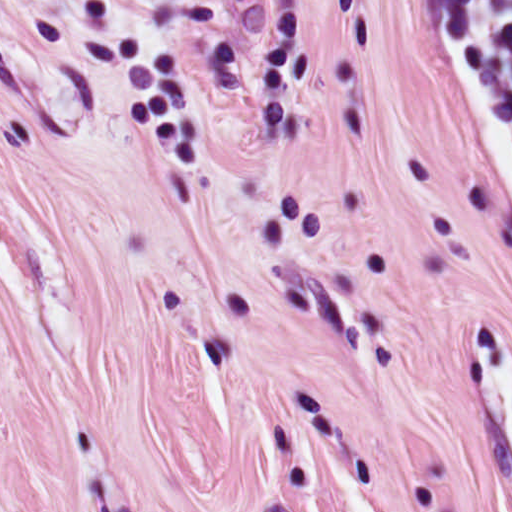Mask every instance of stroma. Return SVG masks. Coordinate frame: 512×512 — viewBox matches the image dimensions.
Instances as JSON below:
<instances>
[{"label":"stroma","instance_id":"stroma-1","mask_svg":"<svg viewBox=\"0 0 512 512\" xmlns=\"http://www.w3.org/2000/svg\"><path fill=\"white\" fill-rule=\"evenodd\" d=\"M479 352L444 0H0V512H512Z\"/></svg>","mask_w":512,"mask_h":512}]
</instances>
